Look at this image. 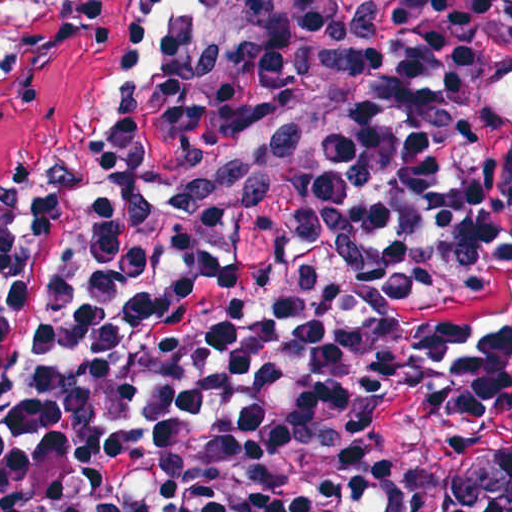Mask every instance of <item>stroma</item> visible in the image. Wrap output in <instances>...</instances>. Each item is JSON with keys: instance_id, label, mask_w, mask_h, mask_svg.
Listing matches in <instances>:
<instances>
[{"instance_id": "1", "label": "stroma", "mask_w": 512, "mask_h": 512, "mask_svg": "<svg viewBox=\"0 0 512 512\" xmlns=\"http://www.w3.org/2000/svg\"><path fill=\"white\" fill-rule=\"evenodd\" d=\"M5 59L0 183L124 105L152 78L160 48L144 0H114V16L71 54ZM366 436L372 454L408 467L430 512H449L484 461L512 454V378L398 398L377 414Z\"/></svg>"}]
</instances>
